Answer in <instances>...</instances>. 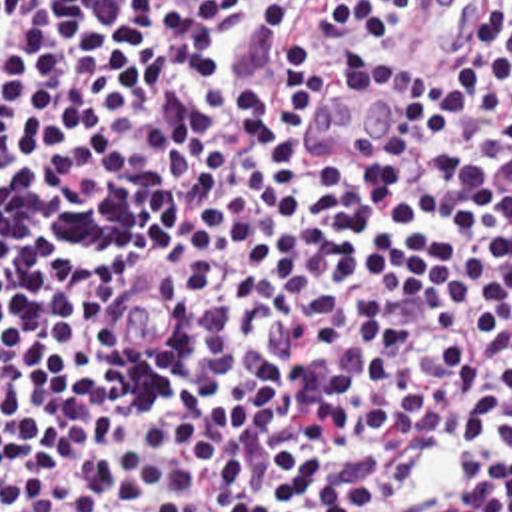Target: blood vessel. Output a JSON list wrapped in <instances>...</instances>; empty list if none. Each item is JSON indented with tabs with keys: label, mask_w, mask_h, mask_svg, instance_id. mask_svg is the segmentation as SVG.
Segmentation results:
<instances>
[{
	"label": "blood vessel",
	"mask_w": 512,
	"mask_h": 512,
	"mask_svg": "<svg viewBox=\"0 0 512 512\" xmlns=\"http://www.w3.org/2000/svg\"><path fill=\"white\" fill-rule=\"evenodd\" d=\"M505 0H435L417 41L389 71L312 105L304 133L326 165H373L393 143L411 91L433 77L455 73L495 41Z\"/></svg>",
	"instance_id": "obj_1"
}]
</instances>
